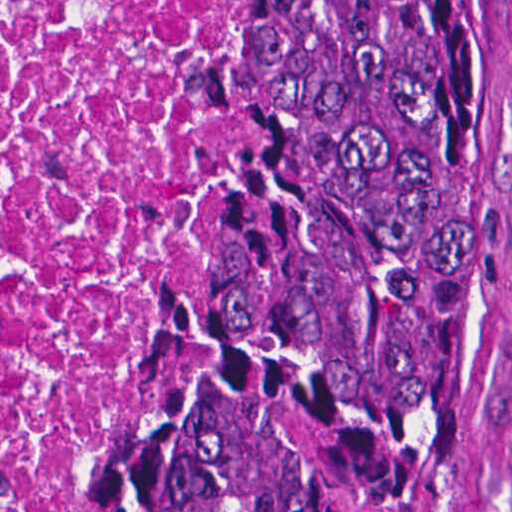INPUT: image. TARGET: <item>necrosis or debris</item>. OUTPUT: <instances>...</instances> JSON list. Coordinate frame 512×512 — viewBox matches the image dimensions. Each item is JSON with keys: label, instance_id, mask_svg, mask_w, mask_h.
I'll list each match as a JSON object with an SVG mask.
<instances>
[{"label": "necrosis or debris", "instance_id": "necrosis-or-debris-1", "mask_svg": "<svg viewBox=\"0 0 512 512\" xmlns=\"http://www.w3.org/2000/svg\"><path fill=\"white\" fill-rule=\"evenodd\" d=\"M236 128V0H0V512L98 443Z\"/></svg>", "mask_w": 512, "mask_h": 512}]
</instances>
